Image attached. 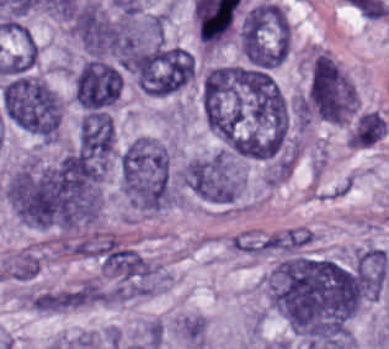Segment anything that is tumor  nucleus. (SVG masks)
<instances>
[{"mask_svg": "<svg viewBox=\"0 0 389 349\" xmlns=\"http://www.w3.org/2000/svg\"><path fill=\"white\" fill-rule=\"evenodd\" d=\"M267 286L274 307L288 322L349 338L361 306L352 264L286 252L272 265Z\"/></svg>", "mask_w": 389, "mask_h": 349, "instance_id": "tumor-nucleus-1", "label": "tumor nucleus"}, {"mask_svg": "<svg viewBox=\"0 0 389 349\" xmlns=\"http://www.w3.org/2000/svg\"><path fill=\"white\" fill-rule=\"evenodd\" d=\"M122 192L140 212L162 210L175 199V187L167 148L150 135L138 134L118 157Z\"/></svg>", "mask_w": 389, "mask_h": 349, "instance_id": "tumor-nucleus-2", "label": "tumor nucleus"}, {"mask_svg": "<svg viewBox=\"0 0 389 349\" xmlns=\"http://www.w3.org/2000/svg\"><path fill=\"white\" fill-rule=\"evenodd\" d=\"M0 101L10 123L41 140H56L62 101L39 76L20 72L8 78L0 90Z\"/></svg>", "mask_w": 389, "mask_h": 349, "instance_id": "tumor-nucleus-3", "label": "tumor nucleus"}, {"mask_svg": "<svg viewBox=\"0 0 389 349\" xmlns=\"http://www.w3.org/2000/svg\"><path fill=\"white\" fill-rule=\"evenodd\" d=\"M358 107L357 88L350 76L327 52H314L304 89V115L346 123L353 119Z\"/></svg>", "mask_w": 389, "mask_h": 349, "instance_id": "tumor-nucleus-4", "label": "tumor nucleus"}, {"mask_svg": "<svg viewBox=\"0 0 389 349\" xmlns=\"http://www.w3.org/2000/svg\"><path fill=\"white\" fill-rule=\"evenodd\" d=\"M239 38L244 55L251 64H280L291 48V27L281 4L262 0L243 13Z\"/></svg>", "mask_w": 389, "mask_h": 349, "instance_id": "tumor-nucleus-5", "label": "tumor nucleus"}, {"mask_svg": "<svg viewBox=\"0 0 389 349\" xmlns=\"http://www.w3.org/2000/svg\"><path fill=\"white\" fill-rule=\"evenodd\" d=\"M177 176L194 196L216 203H232L246 181L242 164L228 152L217 149L189 159Z\"/></svg>", "mask_w": 389, "mask_h": 349, "instance_id": "tumor-nucleus-6", "label": "tumor nucleus"}, {"mask_svg": "<svg viewBox=\"0 0 389 349\" xmlns=\"http://www.w3.org/2000/svg\"><path fill=\"white\" fill-rule=\"evenodd\" d=\"M120 90L117 69L96 59H89L75 77V101L84 110L108 107L120 95Z\"/></svg>", "mask_w": 389, "mask_h": 349, "instance_id": "tumor-nucleus-7", "label": "tumor nucleus"}, {"mask_svg": "<svg viewBox=\"0 0 389 349\" xmlns=\"http://www.w3.org/2000/svg\"><path fill=\"white\" fill-rule=\"evenodd\" d=\"M75 148L98 169L114 159L115 127L109 114H83L78 122Z\"/></svg>", "mask_w": 389, "mask_h": 349, "instance_id": "tumor-nucleus-8", "label": "tumor nucleus"}, {"mask_svg": "<svg viewBox=\"0 0 389 349\" xmlns=\"http://www.w3.org/2000/svg\"><path fill=\"white\" fill-rule=\"evenodd\" d=\"M352 267L362 297L367 301L377 298L389 279V257L374 243L355 249Z\"/></svg>", "mask_w": 389, "mask_h": 349, "instance_id": "tumor-nucleus-9", "label": "tumor nucleus"}, {"mask_svg": "<svg viewBox=\"0 0 389 349\" xmlns=\"http://www.w3.org/2000/svg\"><path fill=\"white\" fill-rule=\"evenodd\" d=\"M387 128V122L380 111H367L358 115L350 135L351 142L358 147L372 144L385 134Z\"/></svg>", "mask_w": 389, "mask_h": 349, "instance_id": "tumor-nucleus-10", "label": "tumor nucleus"}]
</instances>
